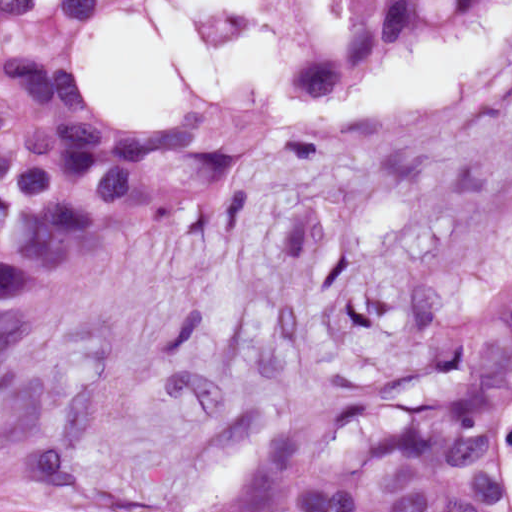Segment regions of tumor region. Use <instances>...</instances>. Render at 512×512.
<instances>
[{"label": "tumor region", "mask_w": 512, "mask_h": 512, "mask_svg": "<svg viewBox=\"0 0 512 512\" xmlns=\"http://www.w3.org/2000/svg\"><path fill=\"white\" fill-rule=\"evenodd\" d=\"M286 1V0H282ZM497 0H336L293 74L335 82L420 22ZM114 0H0V368L25 331L14 293L206 210L268 133L205 104L133 125L101 115L74 31ZM450 186L512 174V81L423 164ZM512 405V277H438L392 294L367 373L253 415L219 474L149 512H509L497 440ZM72 440L0 449V512H64Z\"/></svg>", "instance_id": "e687c5a6"}]
</instances>
